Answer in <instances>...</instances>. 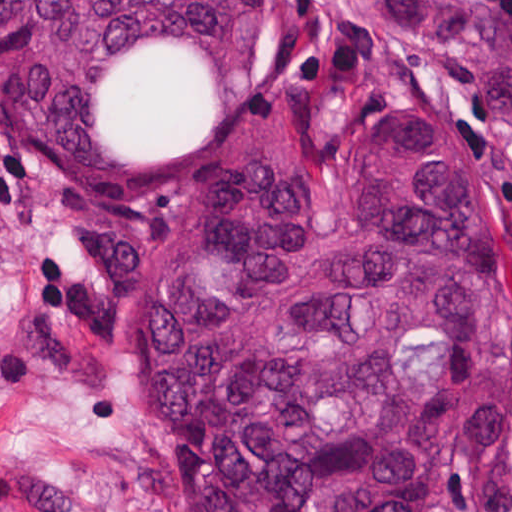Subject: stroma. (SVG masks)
Here are the masks:
<instances>
[{
  "label": "stroma",
  "instance_id": "obj_1",
  "mask_svg": "<svg viewBox=\"0 0 512 512\" xmlns=\"http://www.w3.org/2000/svg\"><path fill=\"white\" fill-rule=\"evenodd\" d=\"M22 49L0 46V512H186L184 465L136 383L134 297L221 187L383 108L442 105L461 126L512 282V124L472 62L400 34L386 0H277L251 104L204 158L127 193L71 190L32 150ZM424 512H512V441L445 456Z\"/></svg>",
  "mask_w": 512,
  "mask_h": 512
}]
</instances>
